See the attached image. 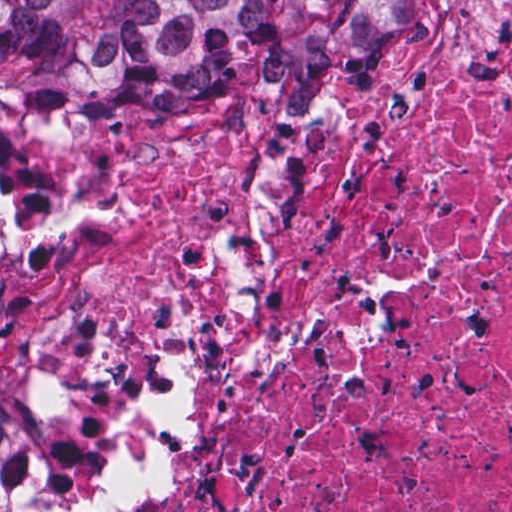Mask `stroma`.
<instances>
[{"instance_id":"35a3bbf8","label":"stroma","mask_w":512,"mask_h":512,"mask_svg":"<svg viewBox=\"0 0 512 512\" xmlns=\"http://www.w3.org/2000/svg\"><path fill=\"white\" fill-rule=\"evenodd\" d=\"M0 1H360V10L335 55H317L286 68L234 64L231 81L176 102L139 105H0V291L15 260L19 193L34 135L56 116L168 113L220 101L246 113L308 119L324 106H346L335 91V70L376 59L429 1L512 0H0ZM19 394L0 375V395ZM0 512H65L55 490L47 448L23 399V433L0 466Z\"/></svg>"}]
</instances>
